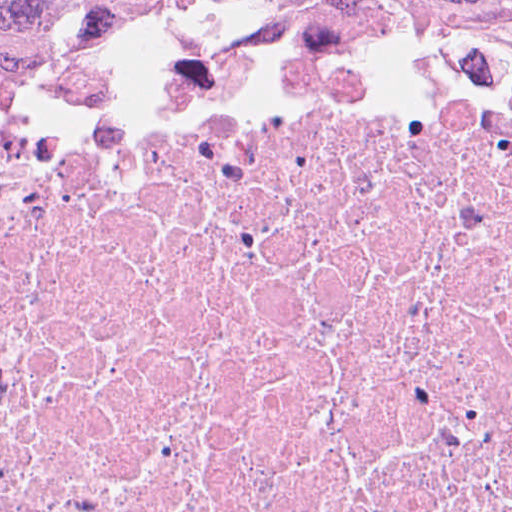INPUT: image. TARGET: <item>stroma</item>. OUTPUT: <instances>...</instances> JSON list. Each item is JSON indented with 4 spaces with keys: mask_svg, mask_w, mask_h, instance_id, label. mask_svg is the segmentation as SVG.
I'll list each match as a JSON object with an SVG mask.
<instances>
[{
    "mask_svg": "<svg viewBox=\"0 0 512 512\" xmlns=\"http://www.w3.org/2000/svg\"><path fill=\"white\" fill-rule=\"evenodd\" d=\"M189 65H316L512 88V41L413 34L347 8H261L214 16L140 34L15 82L0 91V132L106 80Z\"/></svg>",
    "mask_w": 512,
    "mask_h": 512,
    "instance_id": "obj_1",
    "label": "stroma"
}]
</instances>
